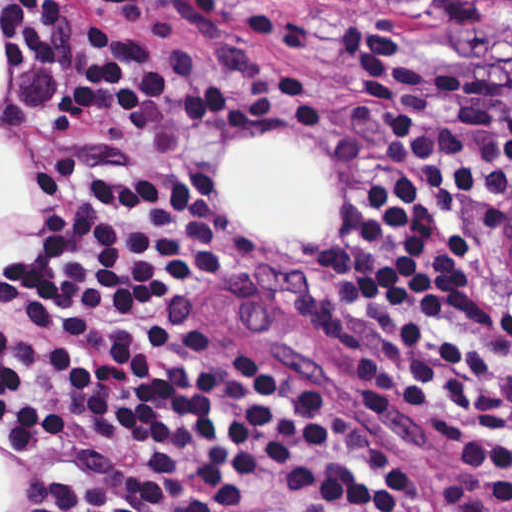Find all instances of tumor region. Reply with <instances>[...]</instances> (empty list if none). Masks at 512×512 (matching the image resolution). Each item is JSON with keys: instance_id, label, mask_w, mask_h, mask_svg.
<instances>
[{"instance_id": "obj_1", "label": "tumor region", "mask_w": 512, "mask_h": 512, "mask_svg": "<svg viewBox=\"0 0 512 512\" xmlns=\"http://www.w3.org/2000/svg\"><path fill=\"white\" fill-rule=\"evenodd\" d=\"M439 25L465 42L512 39V0H422Z\"/></svg>"}]
</instances>
